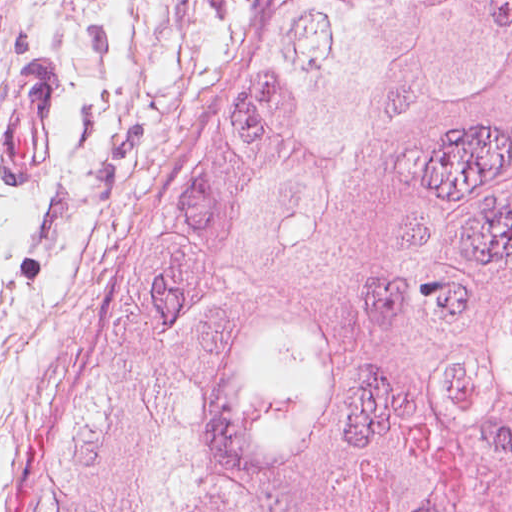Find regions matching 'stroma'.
Masks as SVG:
<instances>
[{
  "label": "stroma",
  "mask_w": 512,
  "mask_h": 512,
  "mask_svg": "<svg viewBox=\"0 0 512 512\" xmlns=\"http://www.w3.org/2000/svg\"><path fill=\"white\" fill-rule=\"evenodd\" d=\"M267 2L0 0V102L31 62L59 66L57 178L0 175V512L25 429Z\"/></svg>",
  "instance_id": "obj_1"
}]
</instances>
